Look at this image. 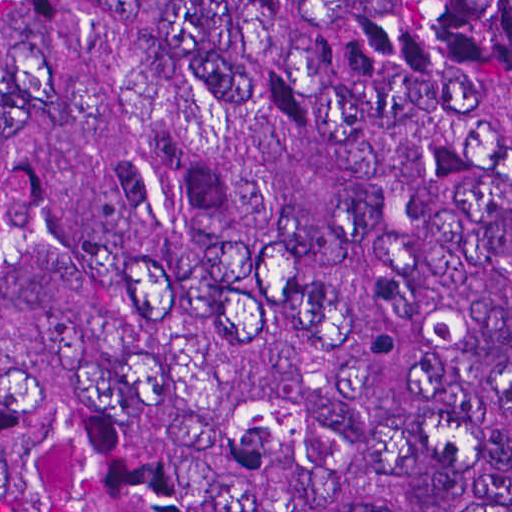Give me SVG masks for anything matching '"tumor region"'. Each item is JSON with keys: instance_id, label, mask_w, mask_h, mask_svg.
<instances>
[{"instance_id": "e687c5a6", "label": "tumor region", "mask_w": 512, "mask_h": 512, "mask_svg": "<svg viewBox=\"0 0 512 512\" xmlns=\"http://www.w3.org/2000/svg\"><path fill=\"white\" fill-rule=\"evenodd\" d=\"M0 512H512V0H0Z\"/></svg>"}]
</instances>
